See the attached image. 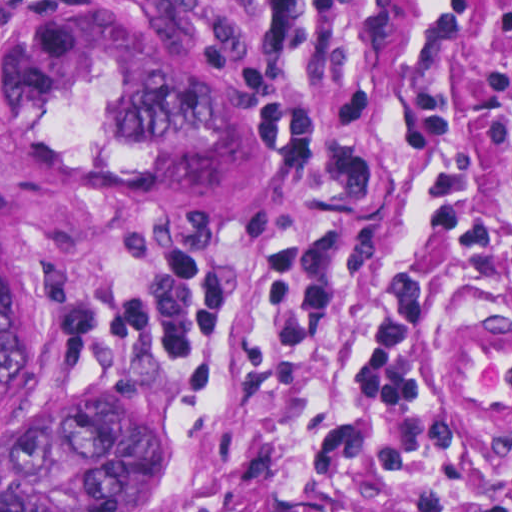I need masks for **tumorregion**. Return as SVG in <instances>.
Here are the masks:
<instances>
[{
	"instance_id": "e687c5a6",
	"label": "tumor region",
	"mask_w": 512,
	"mask_h": 512,
	"mask_svg": "<svg viewBox=\"0 0 512 512\" xmlns=\"http://www.w3.org/2000/svg\"><path fill=\"white\" fill-rule=\"evenodd\" d=\"M0 143L63 207L181 226L287 209L309 121L171 1H18L0 32ZM179 445L157 365L67 361L0 188V512H114L163 486Z\"/></svg>"
}]
</instances>
